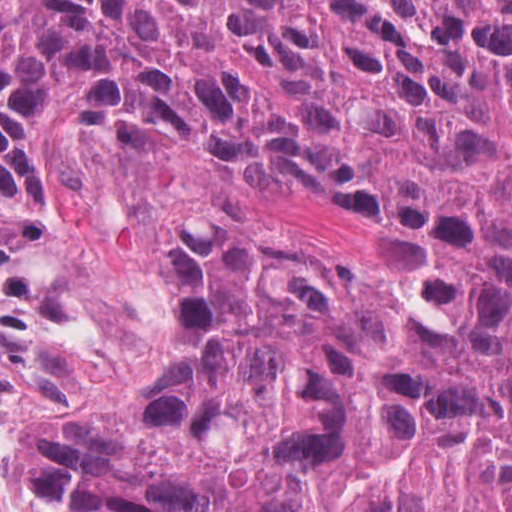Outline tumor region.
Listing matches in <instances>:
<instances>
[{
    "instance_id": "e687c5a6",
    "label": "tumor region",
    "mask_w": 512,
    "mask_h": 512,
    "mask_svg": "<svg viewBox=\"0 0 512 512\" xmlns=\"http://www.w3.org/2000/svg\"><path fill=\"white\" fill-rule=\"evenodd\" d=\"M314 176L386 264L170 215L167 383L0 435L3 512H512V0H0V205L57 124Z\"/></svg>"
}]
</instances>
